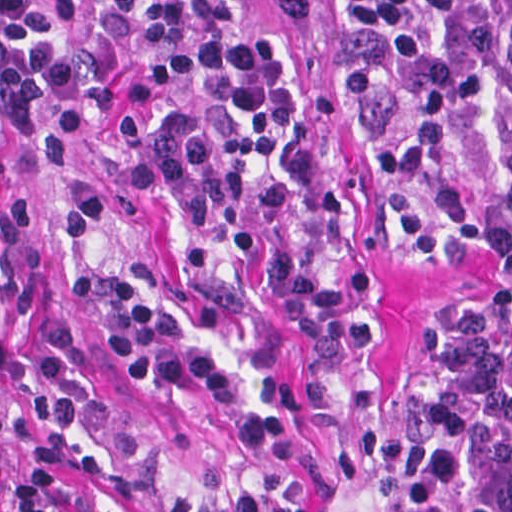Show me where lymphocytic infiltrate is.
Wrapping results in <instances>:
<instances>
[{
	"instance_id": "lymphocytic-infiltrate-1",
	"label": "lymphocytic infiltrate",
	"mask_w": 512,
	"mask_h": 512,
	"mask_svg": "<svg viewBox=\"0 0 512 512\" xmlns=\"http://www.w3.org/2000/svg\"><path fill=\"white\" fill-rule=\"evenodd\" d=\"M199 103L286 169L314 255L352 270L364 228L307 76L273 43L250 0H104ZM343 78L378 110L401 157L414 245L445 260L473 244L512 258V0H335ZM82 24L60 0H0V512H53L42 433L40 351L29 307V234L12 141L39 191L34 226L57 272L139 385H183L211 401L250 463L325 487L338 470L315 433L193 329L159 264L102 265L104 229L177 191L268 270L360 387L371 350L364 304L309 269L290 241L284 179L226 148L203 114L134 137H100L83 108ZM406 512H512V316L466 305L395 397ZM165 512H296L269 492Z\"/></svg>"
}]
</instances>
